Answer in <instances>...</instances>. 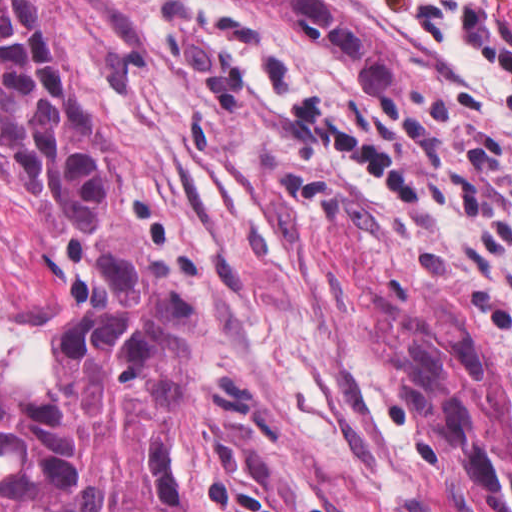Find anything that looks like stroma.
I'll list each match as a JSON object with an SVG mask.
<instances>
[{
    "label": "stroma",
    "mask_w": 512,
    "mask_h": 512,
    "mask_svg": "<svg viewBox=\"0 0 512 512\" xmlns=\"http://www.w3.org/2000/svg\"><path fill=\"white\" fill-rule=\"evenodd\" d=\"M324 1L412 61L403 95L224 0L33 7L204 316L184 512H484L430 460L397 365L425 288L493 324L512 389V89L455 39Z\"/></svg>",
    "instance_id": "35a3bbf8"
}]
</instances>
